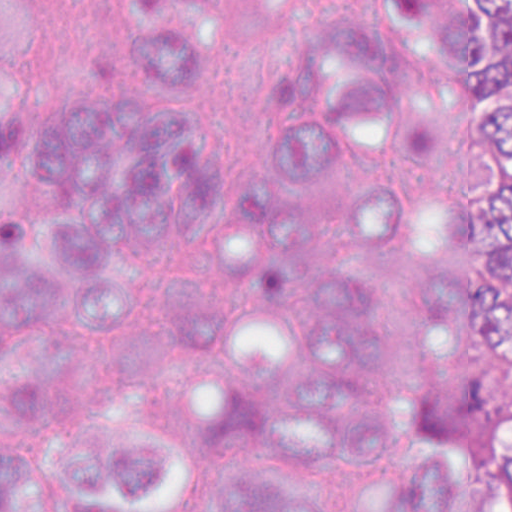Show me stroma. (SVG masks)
Instances as JSON below:
<instances>
[{"mask_svg":"<svg viewBox=\"0 0 512 512\" xmlns=\"http://www.w3.org/2000/svg\"><path fill=\"white\" fill-rule=\"evenodd\" d=\"M455 163V122L448 114V178ZM451 260V238L444 209L437 266ZM476 359V358H475ZM504 368L512 376V364L501 359H479ZM508 442L512 443V422L505 427L449 450H463L480 458L501 462Z\"/></svg>","mask_w":512,"mask_h":512,"instance_id":"35a3bbf8","label":"stroma"}]
</instances>
